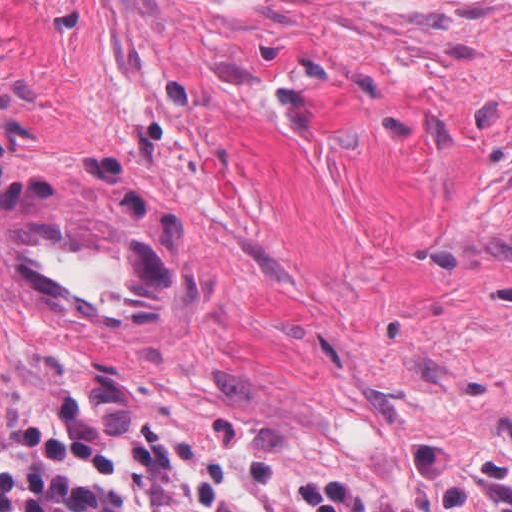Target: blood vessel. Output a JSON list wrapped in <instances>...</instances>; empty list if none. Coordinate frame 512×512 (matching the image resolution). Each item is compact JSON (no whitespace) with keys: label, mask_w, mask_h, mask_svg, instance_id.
Returning a JSON list of instances; mask_svg holds the SVG:
<instances>
[{"label":"blood vessel","mask_w":512,"mask_h":512,"mask_svg":"<svg viewBox=\"0 0 512 512\" xmlns=\"http://www.w3.org/2000/svg\"><path fill=\"white\" fill-rule=\"evenodd\" d=\"M52 203L2 222L10 268L44 310L91 328H156L187 304L186 254L140 223Z\"/></svg>","instance_id":"blood-vessel-1"}]
</instances>
